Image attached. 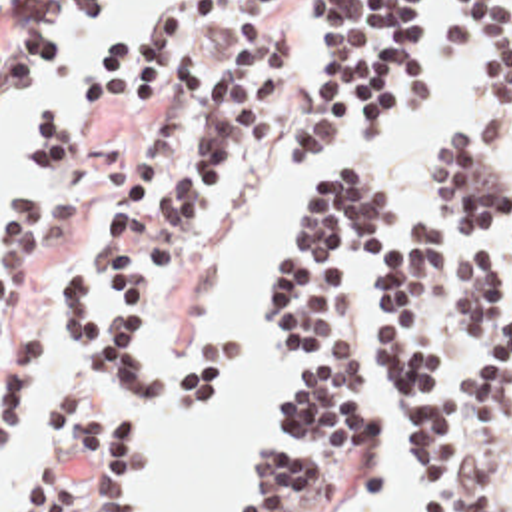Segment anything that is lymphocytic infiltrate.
Segmentation results:
<instances>
[{
  "label": "lymphocytic infiltrate",
  "instance_id": "obj_1",
  "mask_svg": "<svg viewBox=\"0 0 512 512\" xmlns=\"http://www.w3.org/2000/svg\"><path fill=\"white\" fill-rule=\"evenodd\" d=\"M317 51L292 113V45L272 27L286 0H170L130 33L90 49L70 89L122 123L158 109L122 195L94 231L88 265L62 271L48 325L74 353L36 413L12 512H138L144 428L118 409L124 389L186 423L238 381L242 349L212 333L184 357L154 361L156 303L202 245L218 183L284 133L282 161L325 157L359 113L373 147L439 101L425 0H315ZM90 0H18L2 35V85L26 87L56 59L54 37L86 27ZM447 53L473 49L479 99L425 151V209L359 165L307 193L272 269V339L294 377L276 391L284 444L254 458L238 512H353L377 486L379 438L361 399L353 275L383 265L375 317L393 430L409 458L407 512H493L495 484L457 448L455 351L475 345L461 385L467 432L489 428L512 385V0H453L437 25ZM34 175L2 213V434L38 377L30 287L44 253L76 229L82 145L42 117ZM511 251L505 267L493 249ZM445 247L451 259H445ZM512 444V442H509Z\"/></svg>",
  "mask_w": 512,
  "mask_h": 512
}]
</instances>
